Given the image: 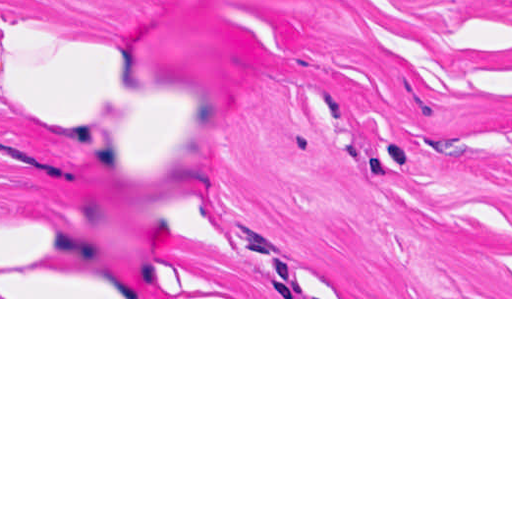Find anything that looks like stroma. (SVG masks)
Wrapping results in <instances>:
<instances>
[{
	"label": "stroma",
	"instance_id": "35a3bbf8",
	"mask_svg": "<svg viewBox=\"0 0 512 512\" xmlns=\"http://www.w3.org/2000/svg\"><path fill=\"white\" fill-rule=\"evenodd\" d=\"M0 299H512V0H0Z\"/></svg>",
	"mask_w": 512,
	"mask_h": 512
}]
</instances>
